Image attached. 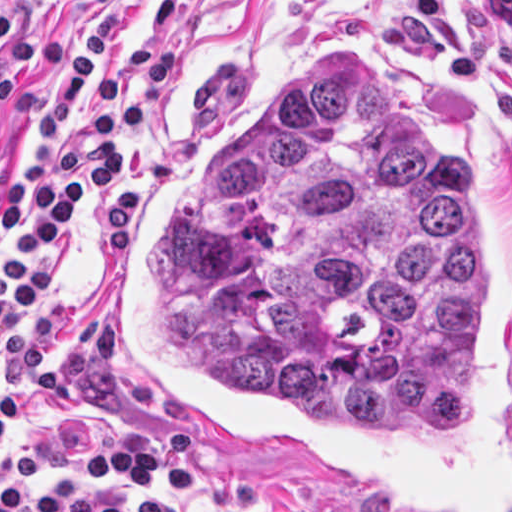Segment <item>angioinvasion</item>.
I'll list each match as a JSON object with an SVG mask.
<instances>
[{
    "instance_id": "1",
    "label": "angioinvasion",
    "mask_w": 512,
    "mask_h": 512,
    "mask_svg": "<svg viewBox=\"0 0 512 512\" xmlns=\"http://www.w3.org/2000/svg\"><path fill=\"white\" fill-rule=\"evenodd\" d=\"M106 353L174 432L366 512H512V190L458 98L308 47L153 171Z\"/></svg>"
}]
</instances>
